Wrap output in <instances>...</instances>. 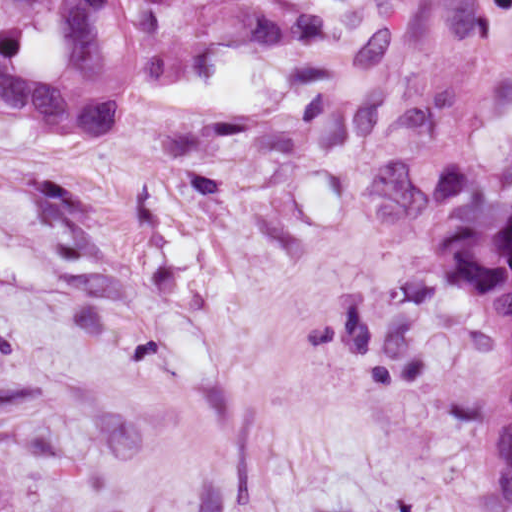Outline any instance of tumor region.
<instances>
[{"label": "tumor region", "instance_id": "tumor-region-1", "mask_svg": "<svg viewBox=\"0 0 512 512\" xmlns=\"http://www.w3.org/2000/svg\"><path fill=\"white\" fill-rule=\"evenodd\" d=\"M326 32L327 12L300 0H0V112L43 133L117 137L136 78L188 83L222 53ZM434 242L505 329L496 478L512 512V189L473 160H436Z\"/></svg>", "mask_w": 512, "mask_h": 512}]
</instances>
